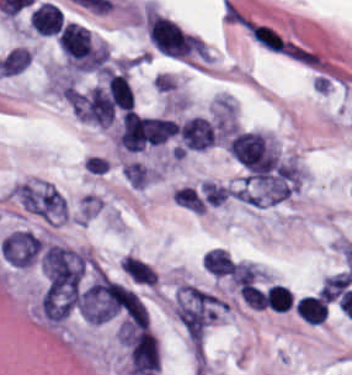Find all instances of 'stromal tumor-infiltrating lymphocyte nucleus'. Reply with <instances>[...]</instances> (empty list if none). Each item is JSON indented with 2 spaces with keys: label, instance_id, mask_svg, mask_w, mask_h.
Masks as SVG:
<instances>
[{
  "label": "stromal tumor-infiltrating lymphocyte nucleus",
  "instance_id": "1",
  "mask_svg": "<svg viewBox=\"0 0 352 375\" xmlns=\"http://www.w3.org/2000/svg\"><path fill=\"white\" fill-rule=\"evenodd\" d=\"M58 44L73 68H99L100 55L89 28L78 22H64L58 36Z\"/></svg>",
  "mask_w": 352,
  "mask_h": 375
},
{
  "label": "stromal tumor-infiltrating lymphocyte nucleus",
  "instance_id": "2",
  "mask_svg": "<svg viewBox=\"0 0 352 375\" xmlns=\"http://www.w3.org/2000/svg\"><path fill=\"white\" fill-rule=\"evenodd\" d=\"M229 148L253 173H264L276 164L279 156L268 138L257 131H237Z\"/></svg>",
  "mask_w": 352,
  "mask_h": 375
},
{
  "label": "stromal tumor-infiltrating lymphocyte nucleus",
  "instance_id": "3",
  "mask_svg": "<svg viewBox=\"0 0 352 375\" xmlns=\"http://www.w3.org/2000/svg\"><path fill=\"white\" fill-rule=\"evenodd\" d=\"M146 23L148 36L159 50L182 58L194 52L195 36L173 20L148 12Z\"/></svg>",
  "mask_w": 352,
  "mask_h": 375
},
{
  "label": "stromal tumor-infiltrating lymphocyte nucleus",
  "instance_id": "4",
  "mask_svg": "<svg viewBox=\"0 0 352 375\" xmlns=\"http://www.w3.org/2000/svg\"><path fill=\"white\" fill-rule=\"evenodd\" d=\"M179 137L187 148L202 149L215 143L216 138L210 120L193 116L179 126Z\"/></svg>",
  "mask_w": 352,
  "mask_h": 375
},
{
  "label": "stromal tumor-infiltrating lymphocyte nucleus",
  "instance_id": "5",
  "mask_svg": "<svg viewBox=\"0 0 352 375\" xmlns=\"http://www.w3.org/2000/svg\"><path fill=\"white\" fill-rule=\"evenodd\" d=\"M31 27L39 34L54 36L59 33L63 14L59 7L52 1H42L30 14Z\"/></svg>",
  "mask_w": 352,
  "mask_h": 375
},
{
  "label": "stromal tumor-infiltrating lymphocyte nucleus",
  "instance_id": "6",
  "mask_svg": "<svg viewBox=\"0 0 352 375\" xmlns=\"http://www.w3.org/2000/svg\"><path fill=\"white\" fill-rule=\"evenodd\" d=\"M296 313L305 322L321 324L328 314V302L321 296L303 295L295 305Z\"/></svg>",
  "mask_w": 352,
  "mask_h": 375
},
{
  "label": "stromal tumor-infiltrating lymphocyte nucleus",
  "instance_id": "7",
  "mask_svg": "<svg viewBox=\"0 0 352 375\" xmlns=\"http://www.w3.org/2000/svg\"><path fill=\"white\" fill-rule=\"evenodd\" d=\"M207 268L215 275H223L233 268V259L225 248L213 247L204 254Z\"/></svg>",
  "mask_w": 352,
  "mask_h": 375
},
{
  "label": "stromal tumor-infiltrating lymphocyte nucleus",
  "instance_id": "8",
  "mask_svg": "<svg viewBox=\"0 0 352 375\" xmlns=\"http://www.w3.org/2000/svg\"><path fill=\"white\" fill-rule=\"evenodd\" d=\"M264 301L274 311H286L293 302V295L284 284H271L264 294Z\"/></svg>",
  "mask_w": 352,
  "mask_h": 375
}]
</instances>
